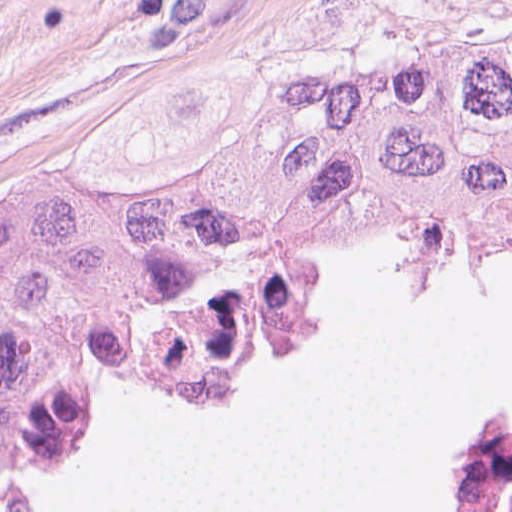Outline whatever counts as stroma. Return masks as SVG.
Returning a JSON list of instances; mask_svg holds the SVG:
<instances>
[{
	"mask_svg": "<svg viewBox=\"0 0 512 512\" xmlns=\"http://www.w3.org/2000/svg\"><path fill=\"white\" fill-rule=\"evenodd\" d=\"M512 32V0H0V180L152 193L284 86Z\"/></svg>",
	"mask_w": 512,
	"mask_h": 512,
	"instance_id": "1",
	"label": "stroma"
}]
</instances>
